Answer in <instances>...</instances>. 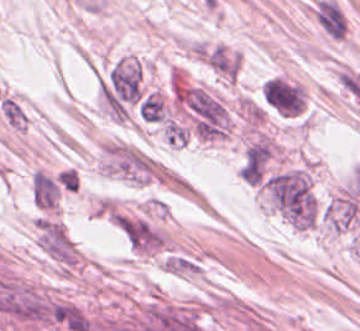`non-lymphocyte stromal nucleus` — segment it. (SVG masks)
Segmentation results:
<instances>
[{"mask_svg":"<svg viewBox=\"0 0 360 331\" xmlns=\"http://www.w3.org/2000/svg\"><path fill=\"white\" fill-rule=\"evenodd\" d=\"M261 93L265 103L282 115H298L304 108V88L287 78L274 76L267 79Z\"/></svg>","mask_w":360,"mask_h":331,"instance_id":"dd21d789","label":"non-lymphocyte stromal nucleus"}]
</instances>
